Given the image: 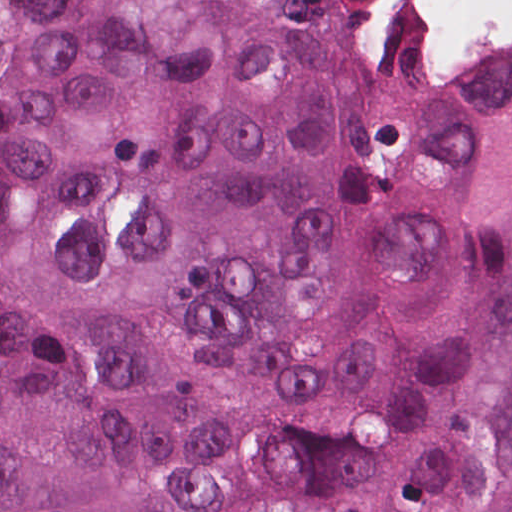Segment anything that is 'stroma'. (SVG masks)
<instances>
[{
    "label": "stroma",
    "instance_id": "1",
    "mask_svg": "<svg viewBox=\"0 0 512 512\" xmlns=\"http://www.w3.org/2000/svg\"><path fill=\"white\" fill-rule=\"evenodd\" d=\"M34 1H356L366 44L383 29L406 21L410 44L419 64L435 80H464L486 74L512 57V44L474 64H453L432 53L424 33L420 1L512 0H0V50Z\"/></svg>",
    "mask_w": 512,
    "mask_h": 512
}]
</instances>
